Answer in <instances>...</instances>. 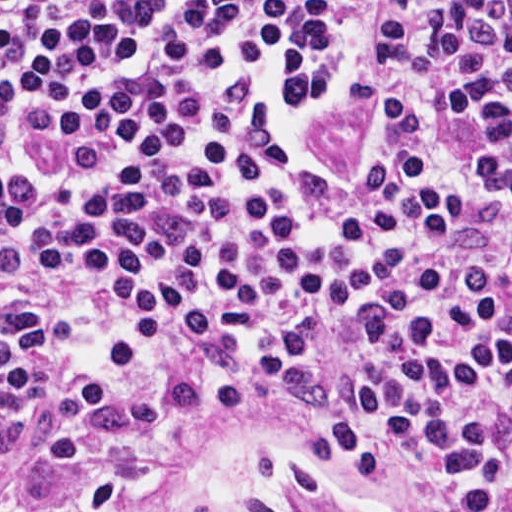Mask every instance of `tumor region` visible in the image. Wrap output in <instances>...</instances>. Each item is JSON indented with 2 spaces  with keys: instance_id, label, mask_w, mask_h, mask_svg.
<instances>
[{
  "instance_id": "obj_1",
  "label": "tumor region",
  "mask_w": 512,
  "mask_h": 512,
  "mask_svg": "<svg viewBox=\"0 0 512 512\" xmlns=\"http://www.w3.org/2000/svg\"><path fill=\"white\" fill-rule=\"evenodd\" d=\"M500 184L512 199V173H503ZM195 228V214L186 207H172L155 218L149 229L154 237L167 246H177L190 237Z\"/></svg>"
}]
</instances>
